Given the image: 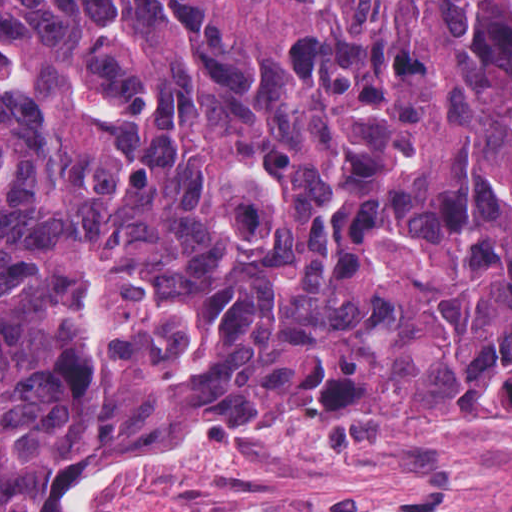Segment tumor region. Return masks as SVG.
I'll use <instances>...</instances> for the list:
<instances>
[{
    "label": "tumor region",
    "mask_w": 512,
    "mask_h": 512,
    "mask_svg": "<svg viewBox=\"0 0 512 512\" xmlns=\"http://www.w3.org/2000/svg\"><path fill=\"white\" fill-rule=\"evenodd\" d=\"M300 419L512 444L493 0H0V512Z\"/></svg>",
    "instance_id": "obj_1"
}]
</instances>
